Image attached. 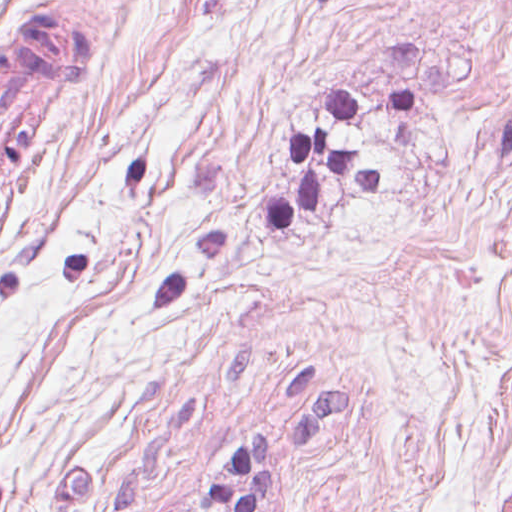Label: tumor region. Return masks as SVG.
I'll return each instance as SVG.
<instances>
[{
    "instance_id": "obj_1",
    "label": "tumor region",
    "mask_w": 512,
    "mask_h": 512,
    "mask_svg": "<svg viewBox=\"0 0 512 512\" xmlns=\"http://www.w3.org/2000/svg\"><path fill=\"white\" fill-rule=\"evenodd\" d=\"M90 63V34L80 19L36 6L0 42L1 215L25 171L50 147L61 124L66 91Z\"/></svg>"
}]
</instances>
